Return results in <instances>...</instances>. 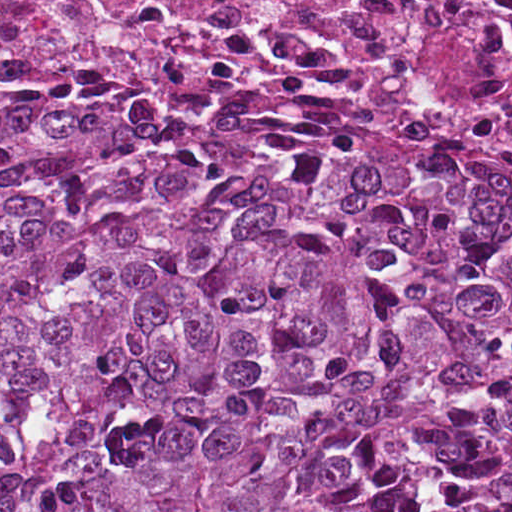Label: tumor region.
I'll list each match as a JSON object with an SVG mask.
<instances>
[{"mask_svg": "<svg viewBox=\"0 0 512 512\" xmlns=\"http://www.w3.org/2000/svg\"><path fill=\"white\" fill-rule=\"evenodd\" d=\"M0 512H512V168L292 83L0 84Z\"/></svg>", "mask_w": 512, "mask_h": 512, "instance_id": "tumor-region-1", "label": "tumor region"}]
</instances>
